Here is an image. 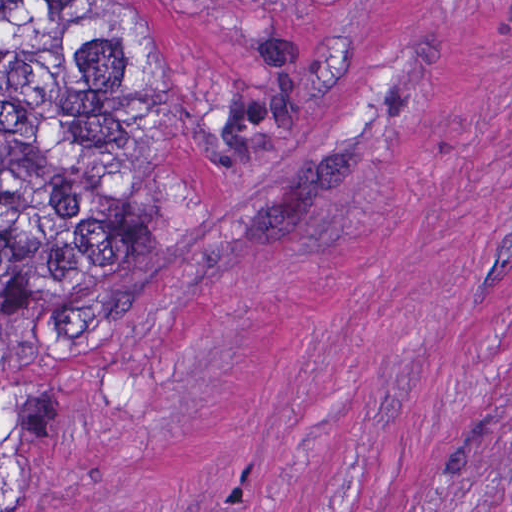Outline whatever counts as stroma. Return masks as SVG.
Returning a JSON list of instances; mask_svg holds the SVG:
<instances>
[{
	"label": "stroma",
	"mask_w": 512,
	"mask_h": 512,
	"mask_svg": "<svg viewBox=\"0 0 512 512\" xmlns=\"http://www.w3.org/2000/svg\"><path fill=\"white\" fill-rule=\"evenodd\" d=\"M113 1L142 258L37 364L34 512H512V0Z\"/></svg>",
	"instance_id": "1"
}]
</instances>
